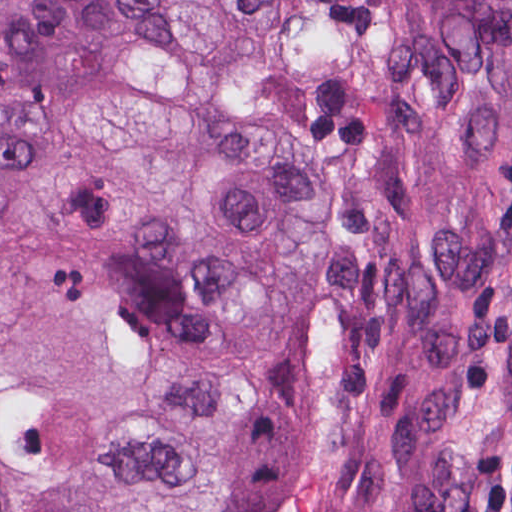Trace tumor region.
I'll list each match as a JSON object with an SVG mask.
<instances>
[{
	"label": "tumor region",
	"mask_w": 512,
	"mask_h": 512,
	"mask_svg": "<svg viewBox=\"0 0 512 512\" xmlns=\"http://www.w3.org/2000/svg\"><path fill=\"white\" fill-rule=\"evenodd\" d=\"M0 512H512V0H0Z\"/></svg>",
	"instance_id": "e687c5a6"
}]
</instances>
